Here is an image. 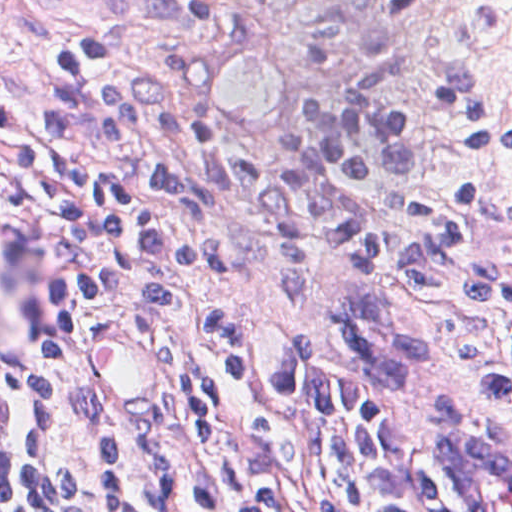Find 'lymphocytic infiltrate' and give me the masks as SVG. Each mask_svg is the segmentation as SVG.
<instances>
[{"mask_svg":"<svg viewBox=\"0 0 512 512\" xmlns=\"http://www.w3.org/2000/svg\"><path fill=\"white\" fill-rule=\"evenodd\" d=\"M416 83L448 137L512 154V122L477 80L387 56L328 88L300 149L243 148L172 60L94 32L48 41L17 88V151L49 218L46 304L77 326L102 307L149 318L193 409L95 422L84 512H424L422 411L435 399L512 413V269L477 248L480 217L512 231V196L380 191L422 171ZM230 236L277 247V293L302 297L313 243L351 258L337 307L348 357L309 337L269 357L190 288L241 274ZM48 414L0 360V512H55Z\"/></svg>","mask_w":512,"mask_h":512,"instance_id":"lymphocytic-infiltrate-1","label":"lymphocytic infiltrate"}]
</instances>
